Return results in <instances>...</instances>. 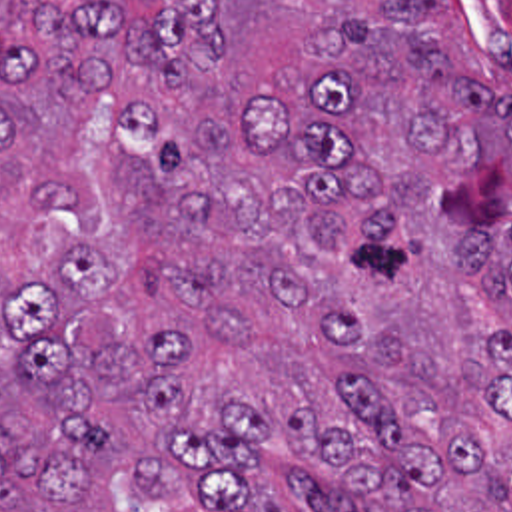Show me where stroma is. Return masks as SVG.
I'll use <instances>...</instances> for the list:
<instances>
[{
    "instance_id": "35a3bbf8",
    "label": "stroma",
    "mask_w": 512,
    "mask_h": 512,
    "mask_svg": "<svg viewBox=\"0 0 512 512\" xmlns=\"http://www.w3.org/2000/svg\"><path fill=\"white\" fill-rule=\"evenodd\" d=\"M491 46L512 66V0H457Z\"/></svg>"
}]
</instances>
